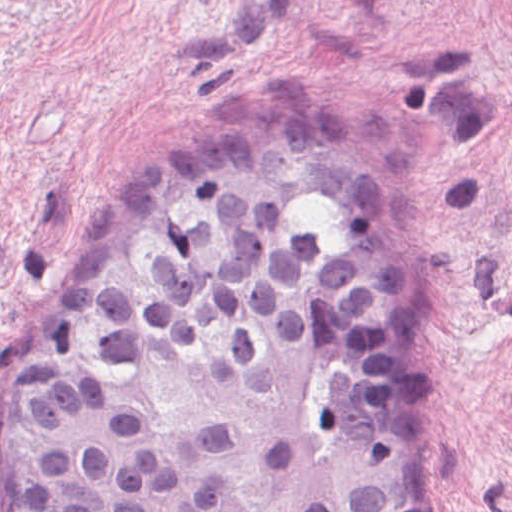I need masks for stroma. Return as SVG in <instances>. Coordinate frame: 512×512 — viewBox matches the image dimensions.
<instances>
[{"instance_id": "stroma-1", "label": "stroma", "mask_w": 512, "mask_h": 512, "mask_svg": "<svg viewBox=\"0 0 512 512\" xmlns=\"http://www.w3.org/2000/svg\"><path fill=\"white\" fill-rule=\"evenodd\" d=\"M279 114L397 190L386 233L274 218L375 284L415 512H512V0H0V385L149 169Z\"/></svg>"}]
</instances>
